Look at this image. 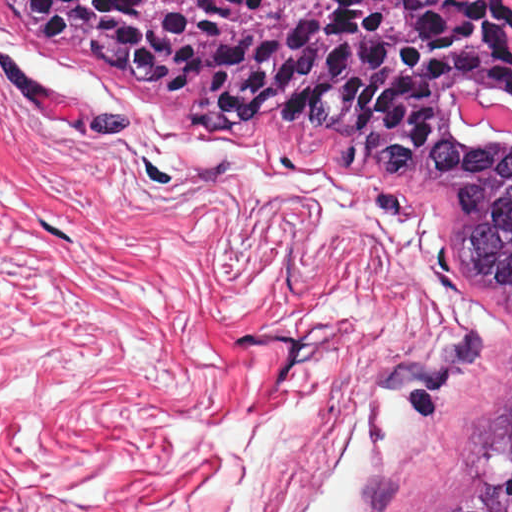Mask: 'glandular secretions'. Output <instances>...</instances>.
I'll return each instance as SVG.
<instances>
[{
    "label": "glandular secretions",
    "mask_w": 512,
    "mask_h": 512,
    "mask_svg": "<svg viewBox=\"0 0 512 512\" xmlns=\"http://www.w3.org/2000/svg\"><path fill=\"white\" fill-rule=\"evenodd\" d=\"M480 99H484L486 101H488V103H492V104H496L498 102H502V103H506V104H509V105H512L511 103H509L508 101L496 96V95H474ZM466 96L460 98L457 100V102L455 103L453 109L455 111V114L458 118H460L464 123L465 120H464V117L462 115V112L460 110V107L464 101ZM469 127H471L473 130H475L477 133L483 135V136H486L488 138H491V139H495V140H498V141H501V142H505V143H509V144H512V139L510 137H508L505 133L497 130L496 128L488 125V124H485L483 123L480 127H476V126H472L468 123H466Z\"/></svg>",
    "instance_id": "glandular-secretions-1"
}]
</instances>
